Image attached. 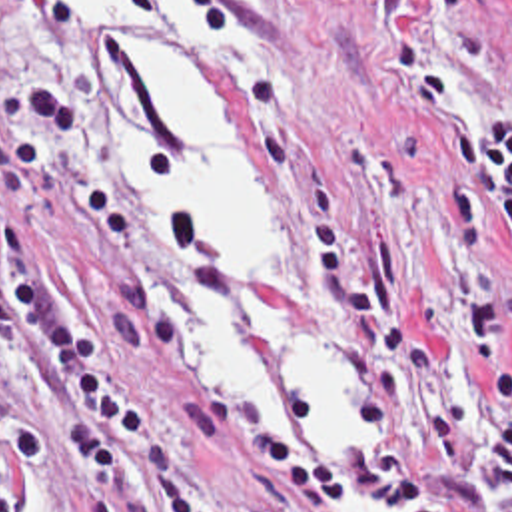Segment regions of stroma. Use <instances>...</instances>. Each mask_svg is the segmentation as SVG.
<instances>
[{
    "label": "stroma",
    "mask_w": 512,
    "mask_h": 512,
    "mask_svg": "<svg viewBox=\"0 0 512 512\" xmlns=\"http://www.w3.org/2000/svg\"><path fill=\"white\" fill-rule=\"evenodd\" d=\"M245 12L263 34L251 48L157 46L243 145L273 215V279L358 339L360 433L382 485L408 512H458L430 473L460 471L494 389L444 281L430 181L446 169L442 119L512 110V0H257ZM115 38L33 0H0V133L23 84L61 90L79 114L35 227L45 285L87 315L111 373L177 437L221 511L346 512L253 343L301 455L243 419L211 369L153 323L143 285H171L175 269L123 201L101 92V46ZM0 213H13L1 185ZM474 251L512 361V243L498 215L484 213ZM223 289L237 305L239 291ZM0 407L45 433L41 461L7 447L13 512H179L161 477L99 475L59 455L61 411L3 329Z\"/></svg>",
    "instance_id": "35a3bbf8"
}]
</instances>
